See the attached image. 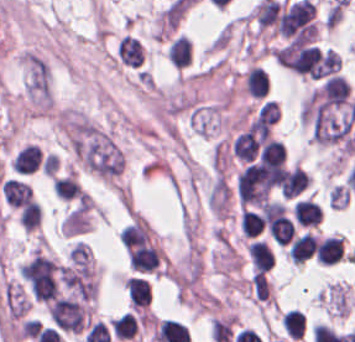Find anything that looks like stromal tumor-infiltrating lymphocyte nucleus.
<instances>
[{"label": "stromal tumor-infiltrating lymphocyte nucleus", "instance_id": "obj_1", "mask_svg": "<svg viewBox=\"0 0 355 342\" xmlns=\"http://www.w3.org/2000/svg\"><path fill=\"white\" fill-rule=\"evenodd\" d=\"M0 191L8 206L21 208L31 201L32 189L29 183L16 178H9L2 182Z\"/></svg>", "mask_w": 355, "mask_h": 342}, {"label": "stromal tumor-infiltrating lymphocyte nucleus", "instance_id": "obj_2", "mask_svg": "<svg viewBox=\"0 0 355 342\" xmlns=\"http://www.w3.org/2000/svg\"><path fill=\"white\" fill-rule=\"evenodd\" d=\"M294 219L299 226L317 227L323 221L321 206L318 201L303 197L293 205Z\"/></svg>", "mask_w": 355, "mask_h": 342}, {"label": "stromal tumor-infiltrating lymphocyte nucleus", "instance_id": "obj_3", "mask_svg": "<svg viewBox=\"0 0 355 342\" xmlns=\"http://www.w3.org/2000/svg\"><path fill=\"white\" fill-rule=\"evenodd\" d=\"M129 305L135 309L146 308L151 299V286L148 278L129 276L126 280Z\"/></svg>", "mask_w": 355, "mask_h": 342}, {"label": "stromal tumor-infiltrating lymphocyte nucleus", "instance_id": "obj_4", "mask_svg": "<svg viewBox=\"0 0 355 342\" xmlns=\"http://www.w3.org/2000/svg\"><path fill=\"white\" fill-rule=\"evenodd\" d=\"M250 265L255 272H262L270 268L273 262V252L266 240L253 238L247 245Z\"/></svg>", "mask_w": 355, "mask_h": 342}, {"label": "stromal tumor-infiltrating lymphocyte nucleus", "instance_id": "obj_5", "mask_svg": "<svg viewBox=\"0 0 355 342\" xmlns=\"http://www.w3.org/2000/svg\"><path fill=\"white\" fill-rule=\"evenodd\" d=\"M243 86L246 92L256 97L266 95L269 89V77L266 68L254 63L247 67L243 77Z\"/></svg>", "mask_w": 355, "mask_h": 342}, {"label": "stromal tumor-infiltrating lymphocyte nucleus", "instance_id": "obj_6", "mask_svg": "<svg viewBox=\"0 0 355 342\" xmlns=\"http://www.w3.org/2000/svg\"><path fill=\"white\" fill-rule=\"evenodd\" d=\"M41 149L34 143H26L13 158V168L17 174H31L40 165Z\"/></svg>", "mask_w": 355, "mask_h": 342}, {"label": "stromal tumor-infiltrating lymphocyte nucleus", "instance_id": "obj_7", "mask_svg": "<svg viewBox=\"0 0 355 342\" xmlns=\"http://www.w3.org/2000/svg\"><path fill=\"white\" fill-rule=\"evenodd\" d=\"M310 176L300 167L292 166L283 170L279 188L283 195L297 196L306 187Z\"/></svg>", "mask_w": 355, "mask_h": 342}, {"label": "stromal tumor-infiltrating lymphocyte nucleus", "instance_id": "obj_8", "mask_svg": "<svg viewBox=\"0 0 355 342\" xmlns=\"http://www.w3.org/2000/svg\"><path fill=\"white\" fill-rule=\"evenodd\" d=\"M167 56L173 66L185 67L192 61V43L186 34H179L172 38Z\"/></svg>", "mask_w": 355, "mask_h": 342}, {"label": "stromal tumor-infiltrating lymphocyte nucleus", "instance_id": "obj_9", "mask_svg": "<svg viewBox=\"0 0 355 342\" xmlns=\"http://www.w3.org/2000/svg\"><path fill=\"white\" fill-rule=\"evenodd\" d=\"M317 240L308 231L296 237L289 247L288 254L293 263L300 264L311 257L317 247Z\"/></svg>", "mask_w": 355, "mask_h": 342}, {"label": "stromal tumor-infiltrating lymphocyte nucleus", "instance_id": "obj_10", "mask_svg": "<svg viewBox=\"0 0 355 342\" xmlns=\"http://www.w3.org/2000/svg\"><path fill=\"white\" fill-rule=\"evenodd\" d=\"M54 193L62 201H70L82 195L81 185L75 174H66L51 180Z\"/></svg>", "mask_w": 355, "mask_h": 342}, {"label": "stromal tumor-infiltrating lymphocyte nucleus", "instance_id": "obj_11", "mask_svg": "<svg viewBox=\"0 0 355 342\" xmlns=\"http://www.w3.org/2000/svg\"><path fill=\"white\" fill-rule=\"evenodd\" d=\"M113 335L117 340L134 337L138 330V319L133 311H126L111 322Z\"/></svg>", "mask_w": 355, "mask_h": 342}, {"label": "stromal tumor-infiltrating lymphocyte nucleus", "instance_id": "obj_12", "mask_svg": "<svg viewBox=\"0 0 355 342\" xmlns=\"http://www.w3.org/2000/svg\"><path fill=\"white\" fill-rule=\"evenodd\" d=\"M243 237L253 238L263 232L264 220L262 214L249 209H242L238 219Z\"/></svg>", "mask_w": 355, "mask_h": 342}, {"label": "stromal tumor-infiltrating lymphocyte nucleus", "instance_id": "obj_13", "mask_svg": "<svg viewBox=\"0 0 355 342\" xmlns=\"http://www.w3.org/2000/svg\"><path fill=\"white\" fill-rule=\"evenodd\" d=\"M282 327L289 337L302 338L305 332L306 316L298 308H291L281 317Z\"/></svg>", "mask_w": 355, "mask_h": 342}, {"label": "stromal tumor-infiltrating lymphocyte nucleus", "instance_id": "obj_14", "mask_svg": "<svg viewBox=\"0 0 355 342\" xmlns=\"http://www.w3.org/2000/svg\"><path fill=\"white\" fill-rule=\"evenodd\" d=\"M42 211L37 201H32L20 209L19 220L21 227L25 231H31L38 226L41 221Z\"/></svg>", "mask_w": 355, "mask_h": 342}]
</instances>
